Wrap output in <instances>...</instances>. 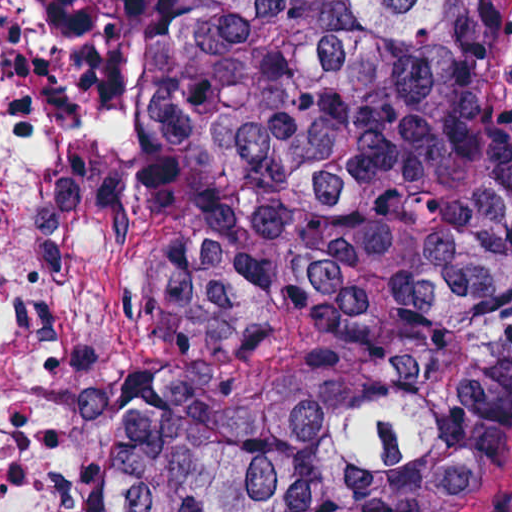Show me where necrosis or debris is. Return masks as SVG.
I'll list each match as a JSON object with an SVG mask.
<instances>
[{
    "mask_svg": "<svg viewBox=\"0 0 512 512\" xmlns=\"http://www.w3.org/2000/svg\"><path fill=\"white\" fill-rule=\"evenodd\" d=\"M76 152L137 184L132 44L110 35L75 95L34 0H0V512H98L111 378L146 365L130 314L45 255L54 169Z\"/></svg>",
    "mask_w": 512,
    "mask_h": 512,
    "instance_id": "necrosis-or-debris-1",
    "label": "necrosis or debris"
}]
</instances>
